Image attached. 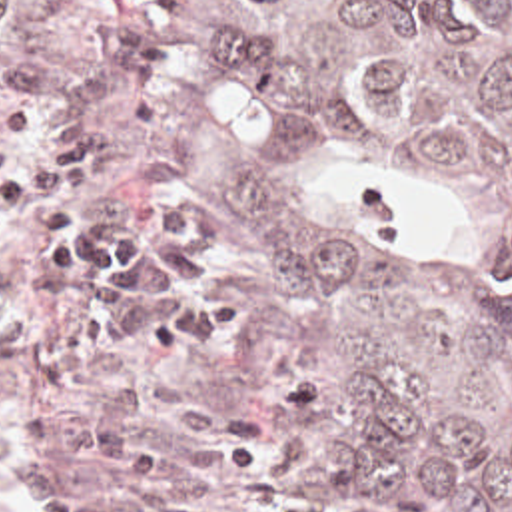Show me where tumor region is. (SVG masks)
<instances>
[{"label": "tumor region", "instance_id": "obj_1", "mask_svg": "<svg viewBox=\"0 0 512 512\" xmlns=\"http://www.w3.org/2000/svg\"><path fill=\"white\" fill-rule=\"evenodd\" d=\"M198 2L268 97L444 235V261L398 263L308 173L190 131L170 159L262 239L258 401L364 447L424 512H512V0Z\"/></svg>", "mask_w": 512, "mask_h": 512}]
</instances>
